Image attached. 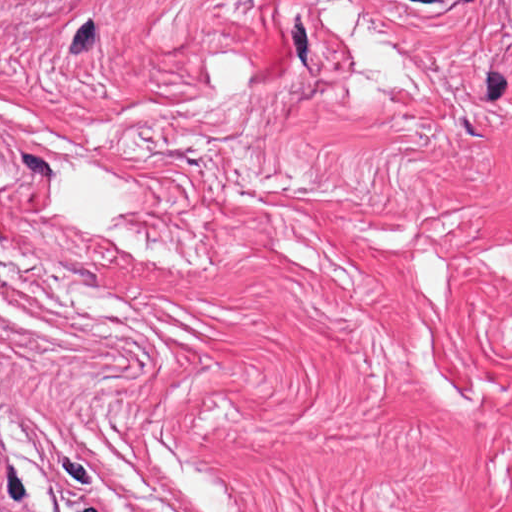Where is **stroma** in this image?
<instances>
[{
  "label": "stroma",
  "mask_w": 512,
  "mask_h": 512,
  "mask_svg": "<svg viewBox=\"0 0 512 512\" xmlns=\"http://www.w3.org/2000/svg\"><path fill=\"white\" fill-rule=\"evenodd\" d=\"M4 512H512V0H0Z\"/></svg>",
  "instance_id": "35a3bbf8"
}]
</instances>
